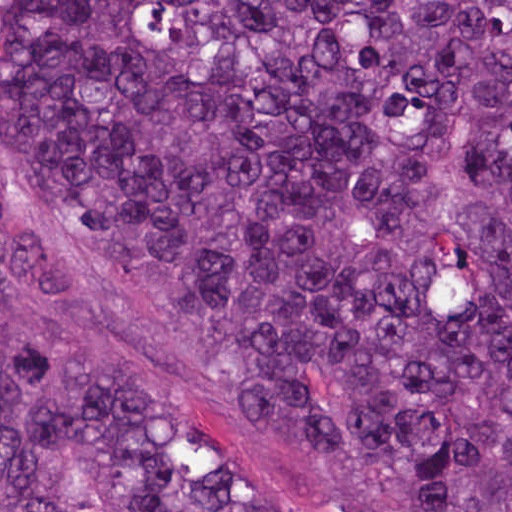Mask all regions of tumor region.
Segmentation results:
<instances>
[{"label":"tumor region","mask_w":512,"mask_h":512,"mask_svg":"<svg viewBox=\"0 0 512 512\" xmlns=\"http://www.w3.org/2000/svg\"><path fill=\"white\" fill-rule=\"evenodd\" d=\"M0 145L297 512H512V0H0ZM0 512H290L0 331Z\"/></svg>","instance_id":"1"}]
</instances>
